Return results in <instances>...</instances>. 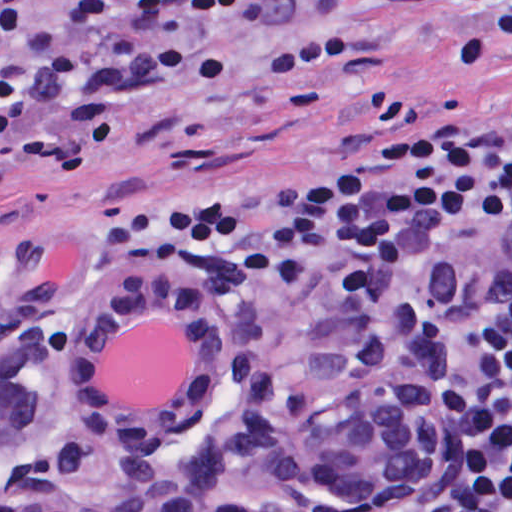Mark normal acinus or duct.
<instances>
[{
  "mask_svg": "<svg viewBox=\"0 0 512 512\" xmlns=\"http://www.w3.org/2000/svg\"><path fill=\"white\" fill-rule=\"evenodd\" d=\"M192 339L168 406L99 384L113 338ZM1 512H465L449 370L383 316L286 311L181 274L1 289Z\"/></svg>",
  "mask_w": 512,
  "mask_h": 512,
  "instance_id": "normal-acinus-or-duct-1",
  "label": "normal acinus or duct"
}]
</instances>
